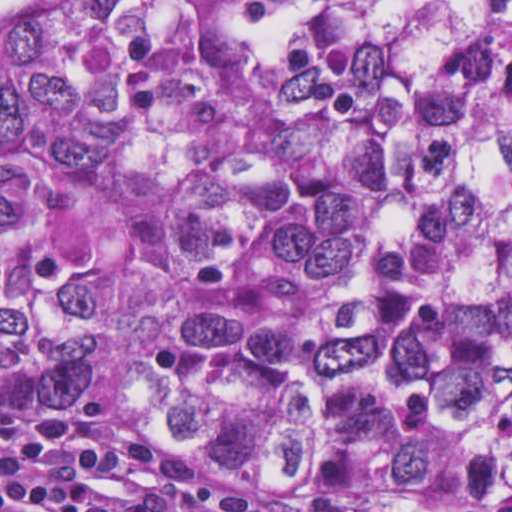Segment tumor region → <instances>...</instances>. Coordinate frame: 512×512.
<instances>
[{
    "mask_svg": "<svg viewBox=\"0 0 512 512\" xmlns=\"http://www.w3.org/2000/svg\"><path fill=\"white\" fill-rule=\"evenodd\" d=\"M191 463L512 502V0H0V411Z\"/></svg>",
    "mask_w": 512,
    "mask_h": 512,
    "instance_id": "obj_1",
    "label": "tumor region"
}]
</instances>
